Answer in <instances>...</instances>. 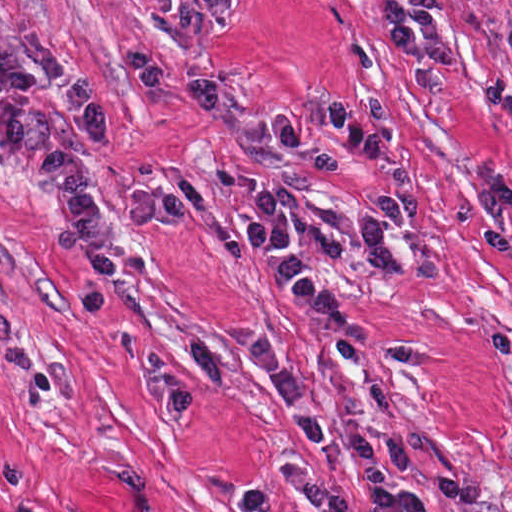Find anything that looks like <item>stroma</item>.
Wrapping results in <instances>:
<instances>
[{
  "label": "stroma",
  "instance_id": "obj_1",
  "mask_svg": "<svg viewBox=\"0 0 512 512\" xmlns=\"http://www.w3.org/2000/svg\"><path fill=\"white\" fill-rule=\"evenodd\" d=\"M447 2L462 63L449 89H409L382 39L383 0H230L197 48L168 37L160 16L136 0H0V44L42 35L104 96L105 145L59 105L44 109L65 132L100 214L137 189H173L187 200L181 229L122 231L120 249L141 256L144 275L115 279L104 316H94L81 298L91 269L52 250L57 219L37 177L25 160L0 153V512H238L249 486L270 490V512H313L289 488L290 468L340 485L356 512H372L356 470L312 448L238 340L274 336L328 407L341 442V400L351 397L378 454L372 394L342 365L339 341L280 300L247 238L246 204L264 186L363 223L391 190L371 159L324 129H311L297 149L268 134L271 113L334 97L374 124L377 154L412 166L419 223L392 239L408 253L429 240L446 284L342 264L291 222L290 247L373 323L370 339L345 342L429 353L416 367L373 365L374 380L404 434L428 438L431 468L485 489L487 501L449 504L408 478L427 512H512V251L477 242L472 196L486 176L512 172V0ZM121 46L164 61L179 84L219 78L220 114L197 115L142 89ZM120 330L156 344L202 387L188 424L160 418L153 378L117 352Z\"/></svg>",
  "mask_w": 512,
  "mask_h": 512
}]
</instances>
